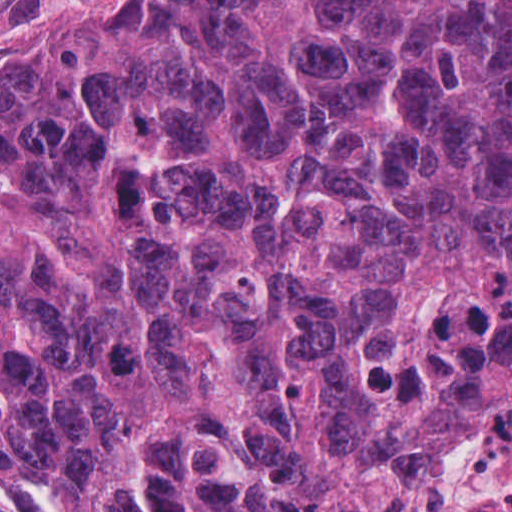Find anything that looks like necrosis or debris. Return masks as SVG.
I'll use <instances>...</instances> for the list:
<instances>
[{
  "mask_svg": "<svg viewBox=\"0 0 512 512\" xmlns=\"http://www.w3.org/2000/svg\"><path fill=\"white\" fill-rule=\"evenodd\" d=\"M447 440L407 481L396 512H512V374L466 319L446 329Z\"/></svg>",
  "mask_w": 512,
  "mask_h": 512,
  "instance_id": "4bbe7bcc",
  "label": "necrosis or debris"
}]
</instances>
